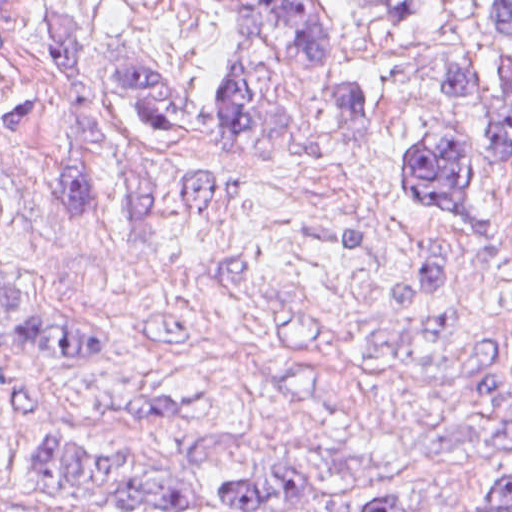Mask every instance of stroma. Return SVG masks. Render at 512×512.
I'll use <instances>...</instances> for the list:
<instances>
[{"label":"stroma","mask_w":512,"mask_h":512,"mask_svg":"<svg viewBox=\"0 0 512 512\" xmlns=\"http://www.w3.org/2000/svg\"><path fill=\"white\" fill-rule=\"evenodd\" d=\"M58 1L0 0V84L51 83ZM63 1L126 59L158 52L217 97L243 82L214 0ZM324 1L349 71L371 90L377 134L330 119L328 73L315 67L279 104L329 134L324 149L162 141L132 105L91 94L125 151L253 192L213 218L59 217L37 184L50 126L0 117V195L34 315L132 355L17 367L0 388V512H142L42 491L49 443L153 467L228 436L233 452L200 475L226 485L267 452L276 425L409 475L403 512L461 511L512 475V168L437 82L466 62H512V42L473 0H436L417 19ZM425 140L468 160L479 199L469 238L399 185L401 156ZM218 377L249 398L192 419L122 406L221 390Z\"/></svg>","instance_id":"1"}]
</instances>
